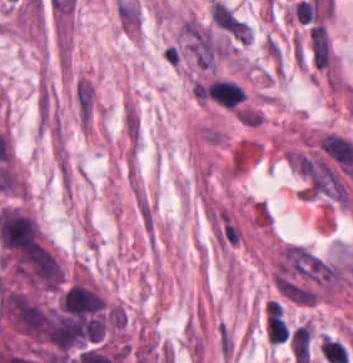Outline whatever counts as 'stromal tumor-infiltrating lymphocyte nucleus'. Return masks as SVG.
I'll return each instance as SVG.
<instances>
[{"mask_svg":"<svg viewBox=\"0 0 353 363\" xmlns=\"http://www.w3.org/2000/svg\"><path fill=\"white\" fill-rule=\"evenodd\" d=\"M209 99L223 108H234L244 95V89L230 79L213 78L203 87Z\"/></svg>","mask_w":353,"mask_h":363,"instance_id":"stromal-tumor-infiltrating-lymphocyte-nucleus-1","label":"stromal tumor-infiltrating lymphocyte nucleus"},{"mask_svg":"<svg viewBox=\"0 0 353 363\" xmlns=\"http://www.w3.org/2000/svg\"><path fill=\"white\" fill-rule=\"evenodd\" d=\"M264 327L267 339L273 342L285 341L289 335L288 326L280 309H267Z\"/></svg>","mask_w":353,"mask_h":363,"instance_id":"stromal-tumor-infiltrating-lymphocyte-nucleus-2","label":"stromal tumor-infiltrating lymphocyte nucleus"},{"mask_svg":"<svg viewBox=\"0 0 353 363\" xmlns=\"http://www.w3.org/2000/svg\"><path fill=\"white\" fill-rule=\"evenodd\" d=\"M310 337V323H302L292 329L289 343L292 355L296 363L307 358Z\"/></svg>","mask_w":353,"mask_h":363,"instance_id":"stromal-tumor-infiltrating-lymphocyte-nucleus-3","label":"stromal tumor-infiltrating lymphocyte nucleus"}]
</instances>
